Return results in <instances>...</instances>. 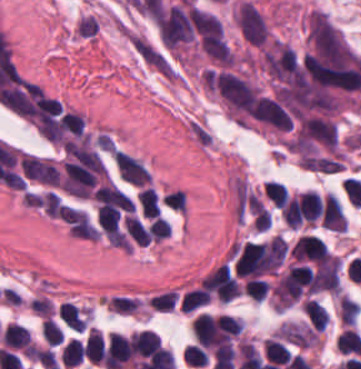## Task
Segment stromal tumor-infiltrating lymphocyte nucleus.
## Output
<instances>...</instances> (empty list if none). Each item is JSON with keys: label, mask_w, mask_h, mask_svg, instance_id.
Masks as SVG:
<instances>
[{"label": "stromal tumor-infiltrating lymphocyte nucleus", "mask_w": 361, "mask_h": 369, "mask_svg": "<svg viewBox=\"0 0 361 369\" xmlns=\"http://www.w3.org/2000/svg\"><path fill=\"white\" fill-rule=\"evenodd\" d=\"M105 340L102 331L91 328L84 345V353L92 365H102Z\"/></svg>", "instance_id": "stromal-tumor-infiltrating-lymphocyte-nucleus-2"}, {"label": "stromal tumor-infiltrating lymphocyte nucleus", "mask_w": 361, "mask_h": 369, "mask_svg": "<svg viewBox=\"0 0 361 369\" xmlns=\"http://www.w3.org/2000/svg\"><path fill=\"white\" fill-rule=\"evenodd\" d=\"M64 331L50 317H43L40 323V335L43 341L49 346L60 345Z\"/></svg>", "instance_id": "stromal-tumor-infiltrating-lymphocyte-nucleus-7"}, {"label": "stromal tumor-infiltrating lymphocyte nucleus", "mask_w": 361, "mask_h": 369, "mask_svg": "<svg viewBox=\"0 0 361 369\" xmlns=\"http://www.w3.org/2000/svg\"><path fill=\"white\" fill-rule=\"evenodd\" d=\"M265 197L275 206L282 207L286 202L288 189L278 181H265L262 184Z\"/></svg>", "instance_id": "stromal-tumor-infiltrating-lymphocyte-nucleus-8"}, {"label": "stromal tumor-infiltrating lymphocyte nucleus", "mask_w": 361, "mask_h": 369, "mask_svg": "<svg viewBox=\"0 0 361 369\" xmlns=\"http://www.w3.org/2000/svg\"><path fill=\"white\" fill-rule=\"evenodd\" d=\"M84 358L83 344L78 339H71L62 349V365L73 369Z\"/></svg>", "instance_id": "stromal-tumor-infiltrating-lymphocyte-nucleus-6"}, {"label": "stromal tumor-infiltrating lymphocyte nucleus", "mask_w": 361, "mask_h": 369, "mask_svg": "<svg viewBox=\"0 0 361 369\" xmlns=\"http://www.w3.org/2000/svg\"><path fill=\"white\" fill-rule=\"evenodd\" d=\"M132 348L139 355H150L160 346L159 339L150 330L134 332L131 336Z\"/></svg>", "instance_id": "stromal-tumor-infiltrating-lymphocyte-nucleus-3"}, {"label": "stromal tumor-infiltrating lymphocyte nucleus", "mask_w": 361, "mask_h": 369, "mask_svg": "<svg viewBox=\"0 0 361 369\" xmlns=\"http://www.w3.org/2000/svg\"><path fill=\"white\" fill-rule=\"evenodd\" d=\"M0 342L12 350H25L33 345L29 330L21 323L8 322L2 330Z\"/></svg>", "instance_id": "stromal-tumor-infiltrating-lymphocyte-nucleus-1"}, {"label": "stromal tumor-infiltrating lymphocyte nucleus", "mask_w": 361, "mask_h": 369, "mask_svg": "<svg viewBox=\"0 0 361 369\" xmlns=\"http://www.w3.org/2000/svg\"><path fill=\"white\" fill-rule=\"evenodd\" d=\"M186 363L192 367H206L208 365V355L205 350L196 343L187 346L182 354Z\"/></svg>", "instance_id": "stromal-tumor-infiltrating-lymphocyte-nucleus-11"}, {"label": "stromal tumor-infiltrating lymphocyte nucleus", "mask_w": 361, "mask_h": 369, "mask_svg": "<svg viewBox=\"0 0 361 369\" xmlns=\"http://www.w3.org/2000/svg\"><path fill=\"white\" fill-rule=\"evenodd\" d=\"M141 304L138 297L117 295L107 302L109 311L121 314H133Z\"/></svg>", "instance_id": "stromal-tumor-infiltrating-lymphocyte-nucleus-9"}, {"label": "stromal tumor-infiltrating lymphocyte nucleus", "mask_w": 361, "mask_h": 369, "mask_svg": "<svg viewBox=\"0 0 361 369\" xmlns=\"http://www.w3.org/2000/svg\"><path fill=\"white\" fill-rule=\"evenodd\" d=\"M243 288L246 294L261 303L267 296L269 284L261 277H247Z\"/></svg>", "instance_id": "stromal-tumor-infiltrating-lymphocyte-nucleus-10"}, {"label": "stromal tumor-infiltrating lymphocyte nucleus", "mask_w": 361, "mask_h": 369, "mask_svg": "<svg viewBox=\"0 0 361 369\" xmlns=\"http://www.w3.org/2000/svg\"><path fill=\"white\" fill-rule=\"evenodd\" d=\"M309 322L319 331H323L328 316L315 298H307L301 306Z\"/></svg>", "instance_id": "stromal-tumor-infiltrating-lymphocyte-nucleus-5"}, {"label": "stromal tumor-infiltrating lymphocyte nucleus", "mask_w": 361, "mask_h": 369, "mask_svg": "<svg viewBox=\"0 0 361 369\" xmlns=\"http://www.w3.org/2000/svg\"><path fill=\"white\" fill-rule=\"evenodd\" d=\"M210 299L209 293L202 286L191 288L182 296L181 309L192 313L209 303Z\"/></svg>", "instance_id": "stromal-tumor-infiltrating-lymphocyte-nucleus-4"}]
</instances>
